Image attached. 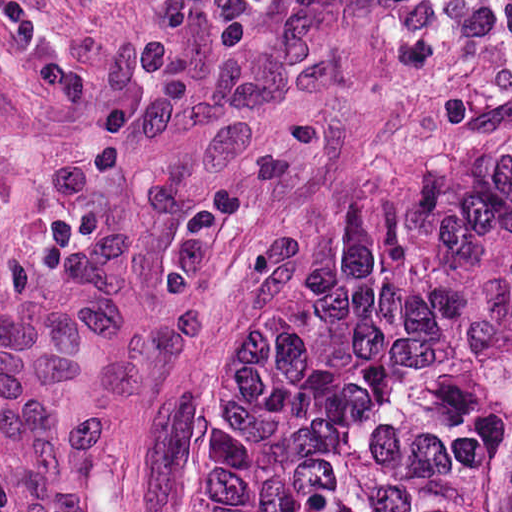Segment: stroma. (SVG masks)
I'll return each instance as SVG.
<instances>
[{
  "label": "stroma",
  "mask_w": 512,
  "mask_h": 512,
  "mask_svg": "<svg viewBox=\"0 0 512 512\" xmlns=\"http://www.w3.org/2000/svg\"><path fill=\"white\" fill-rule=\"evenodd\" d=\"M512 135V0H0V512H185L277 236Z\"/></svg>",
  "instance_id": "35a3bbf8"
}]
</instances>
